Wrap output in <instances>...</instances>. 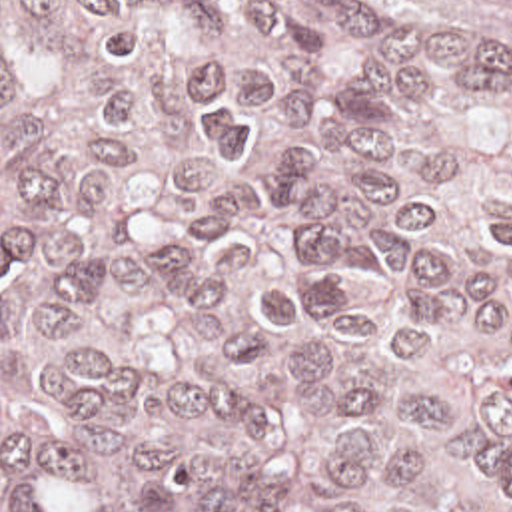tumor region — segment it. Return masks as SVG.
Returning a JSON list of instances; mask_svg holds the SVG:
<instances>
[{"instance_id": "tumor-region-1", "label": "tumor region", "mask_w": 512, "mask_h": 512, "mask_svg": "<svg viewBox=\"0 0 512 512\" xmlns=\"http://www.w3.org/2000/svg\"><path fill=\"white\" fill-rule=\"evenodd\" d=\"M0 512H512V0H0Z\"/></svg>"}]
</instances>
